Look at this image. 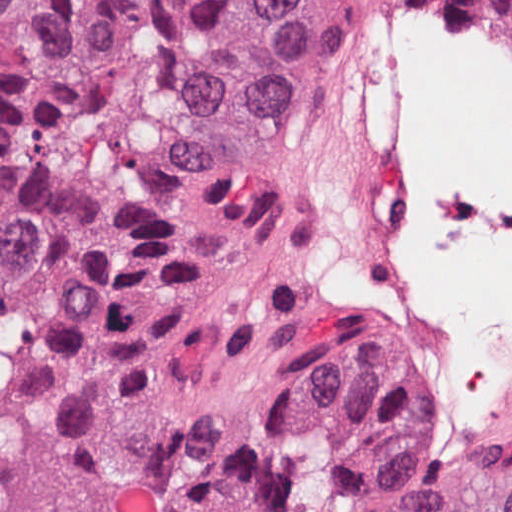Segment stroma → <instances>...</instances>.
Segmentation results:
<instances>
[{"label":"stroma","mask_w":512,"mask_h":512,"mask_svg":"<svg viewBox=\"0 0 512 512\" xmlns=\"http://www.w3.org/2000/svg\"><path fill=\"white\" fill-rule=\"evenodd\" d=\"M452 1L462 5L471 17L498 38L512 44V35L491 22L471 0ZM413 42L401 55L384 85L400 74ZM325 162L302 178L314 282L312 315L334 330L376 345L442 376L435 345L420 327L394 316L386 309L350 301L340 296L330 284L333 249L320 204L308 194Z\"/></svg>","instance_id":"35a3bbf8"}]
</instances>
